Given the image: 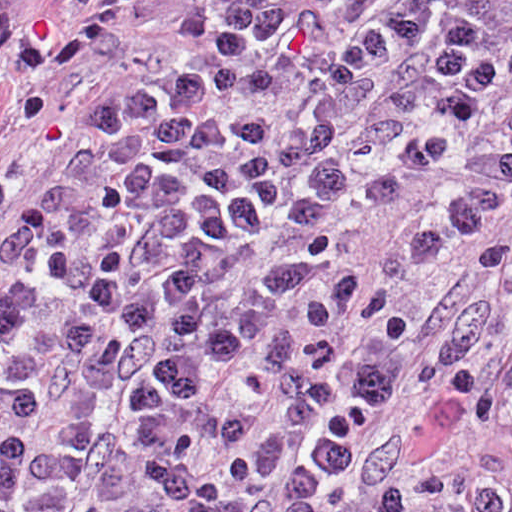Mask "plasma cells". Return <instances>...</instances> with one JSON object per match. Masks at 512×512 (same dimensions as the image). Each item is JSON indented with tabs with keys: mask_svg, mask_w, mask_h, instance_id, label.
I'll return each instance as SVG.
<instances>
[{
	"mask_svg": "<svg viewBox=\"0 0 512 512\" xmlns=\"http://www.w3.org/2000/svg\"><path fill=\"white\" fill-rule=\"evenodd\" d=\"M156 0H61L48 71L117 61ZM1 0V205L53 124ZM442 178L409 256L479 227L474 302L428 343L434 424L512 439V0H206L157 65L99 88L1 229V512H346L413 325L351 243ZM408 476L371 512H499Z\"/></svg>",
	"mask_w": 512,
	"mask_h": 512,
	"instance_id": "plasma-cells-1",
	"label": "plasma cells"
}]
</instances>
